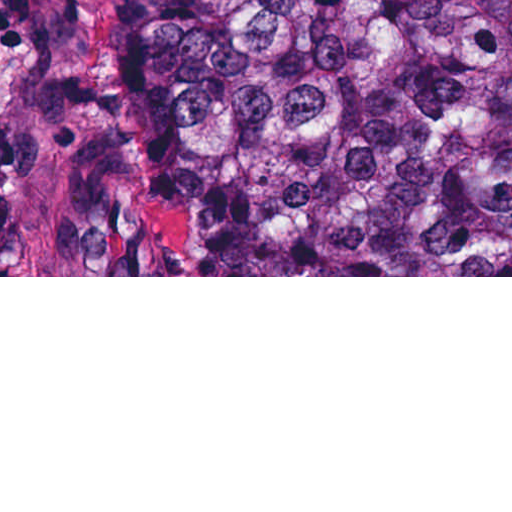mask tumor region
<instances>
[{"label": "tumor region", "instance_id": "obj_1", "mask_svg": "<svg viewBox=\"0 0 512 512\" xmlns=\"http://www.w3.org/2000/svg\"><path fill=\"white\" fill-rule=\"evenodd\" d=\"M2 266L512 275V0H149L125 184L0 143Z\"/></svg>", "mask_w": 512, "mask_h": 512}]
</instances>
